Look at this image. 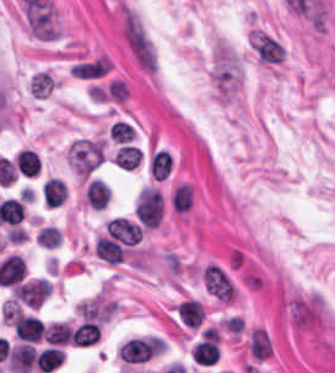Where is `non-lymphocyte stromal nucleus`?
<instances>
[{
    "mask_svg": "<svg viewBox=\"0 0 335 373\" xmlns=\"http://www.w3.org/2000/svg\"><path fill=\"white\" fill-rule=\"evenodd\" d=\"M117 26L130 59L141 72L153 76L157 70L153 40L139 13L122 0L119 4Z\"/></svg>",
    "mask_w": 335,
    "mask_h": 373,
    "instance_id": "dd21d789",
    "label": "non-lymphocyte stromal nucleus"
}]
</instances>
